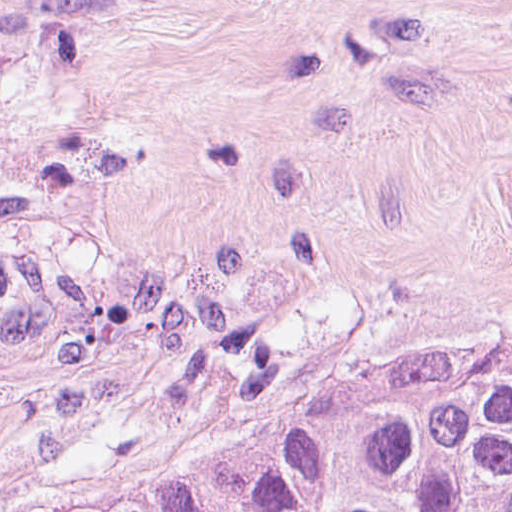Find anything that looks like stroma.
Wrapping results in <instances>:
<instances>
[{"mask_svg": "<svg viewBox=\"0 0 512 512\" xmlns=\"http://www.w3.org/2000/svg\"><path fill=\"white\" fill-rule=\"evenodd\" d=\"M368 361H512V0H0V512Z\"/></svg>", "mask_w": 512, "mask_h": 512, "instance_id": "obj_1", "label": "stroma"}]
</instances>
